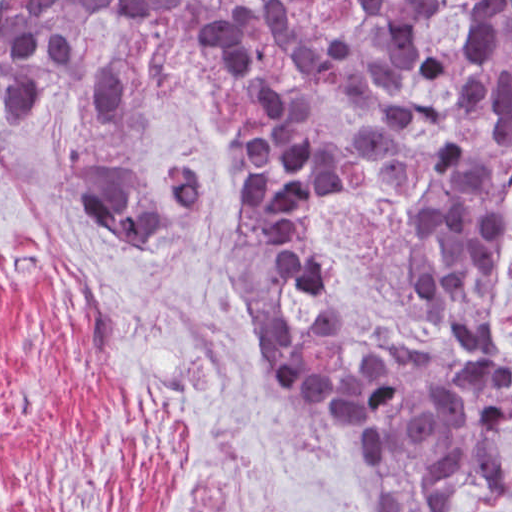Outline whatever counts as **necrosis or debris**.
Here are the masks:
<instances>
[{"instance_id": "obj_1", "label": "necrosis or debris", "mask_w": 512, "mask_h": 512, "mask_svg": "<svg viewBox=\"0 0 512 512\" xmlns=\"http://www.w3.org/2000/svg\"><path fill=\"white\" fill-rule=\"evenodd\" d=\"M509 0H211L202 71L284 126L250 202L298 338L431 337L445 323L421 240L428 196L512 147Z\"/></svg>"}]
</instances>
